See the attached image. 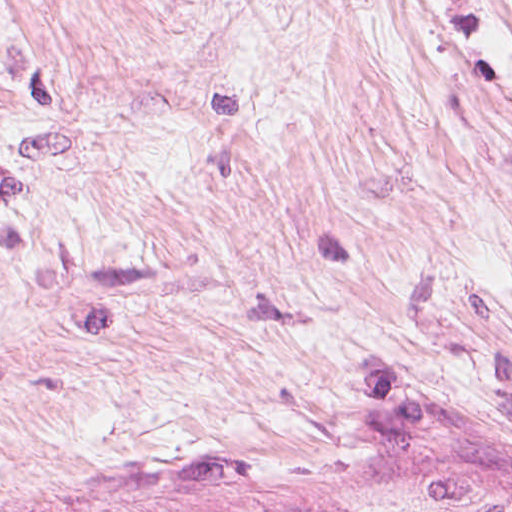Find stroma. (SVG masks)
Returning <instances> with one entry per match:
<instances>
[{"label": "stroma", "mask_w": 512, "mask_h": 512, "mask_svg": "<svg viewBox=\"0 0 512 512\" xmlns=\"http://www.w3.org/2000/svg\"><path fill=\"white\" fill-rule=\"evenodd\" d=\"M512 509V0H0V512Z\"/></svg>", "instance_id": "1"}]
</instances>
